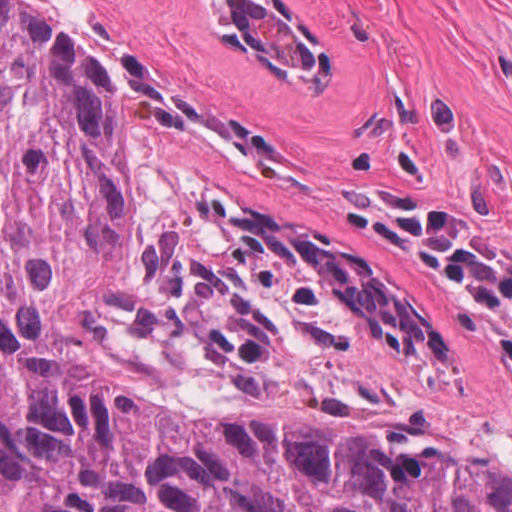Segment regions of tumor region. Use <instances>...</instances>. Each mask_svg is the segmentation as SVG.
<instances>
[{"mask_svg": "<svg viewBox=\"0 0 512 512\" xmlns=\"http://www.w3.org/2000/svg\"><path fill=\"white\" fill-rule=\"evenodd\" d=\"M224 191L126 157L98 63L0 0V512H512L502 465L311 366L457 348Z\"/></svg>", "mask_w": 512, "mask_h": 512, "instance_id": "1", "label": "tumor region"}]
</instances>
